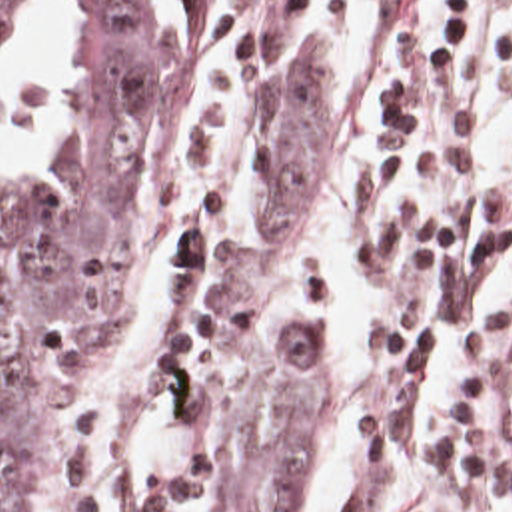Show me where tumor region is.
I'll use <instances>...</instances> for the list:
<instances>
[{"instance_id":"e687c5a6","label":"tumor region","mask_w":512,"mask_h":512,"mask_svg":"<svg viewBox=\"0 0 512 512\" xmlns=\"http://www.w3.org/2000/svg\"><path fill=\"white\" fill-rule=\"evenodd\" d=\"M83 72L67 120L23 184L0 192V512H67V403L93 358L151 154L181 0H73ZM23 0H0V38ZM323 50L285 62L267 108V200L205 306L231 379L235 512H309L319 479L327 328L285 320L283 266L321 168Z\"/></svg>"}]
</instances>
